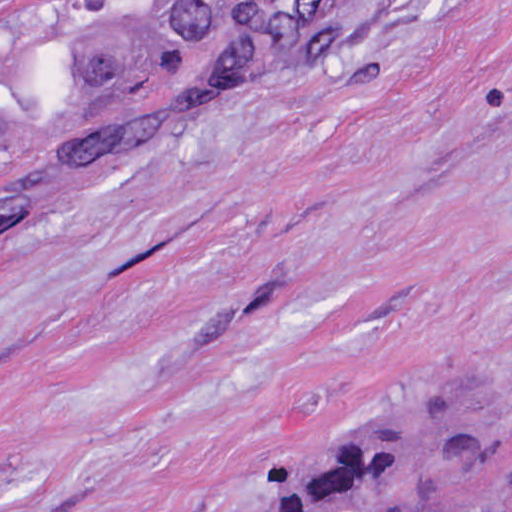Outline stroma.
Segmentation results:
<instances>
[{"label":"stroma","mask_w":512,"mask_h":512,"mask_svg":"<svg viewBox=\"0 0 512 512\" xmlns=\"http://www.w3.org/2000/svg\"><path fill=\"white\" fill-rule=\"evenodd\" d=\"M0 1H299L0 228V512H249L442 383L500 447L441 512H512V0Z\"/></svg>","instance_id":"obj_1"}]
</instances>
